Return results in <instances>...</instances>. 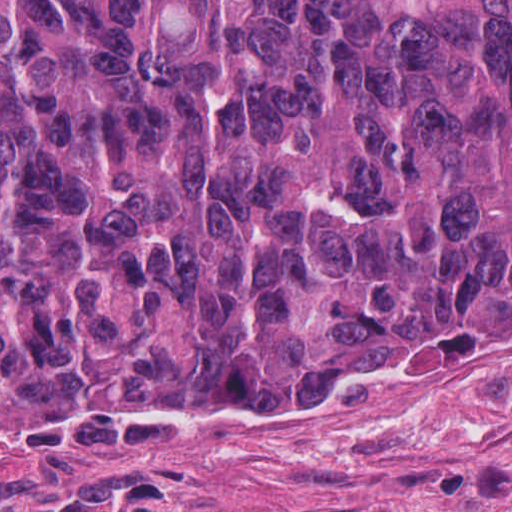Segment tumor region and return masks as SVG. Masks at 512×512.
<instances>
[{"label": "tumor region", "instance_id": "tumor-region-1", "mask_svg": "<svg viewBox=\"0 0 512 512\" xmlns=\"http://www.w3.org/2000/svg\"><path fill=\"white\" fill-rule=\"evenodd\" d=\"M511 330L512 1L0 0V416Z\"/></svg>", "mask_w": 512, "mask_h": 512}]
</instances>
